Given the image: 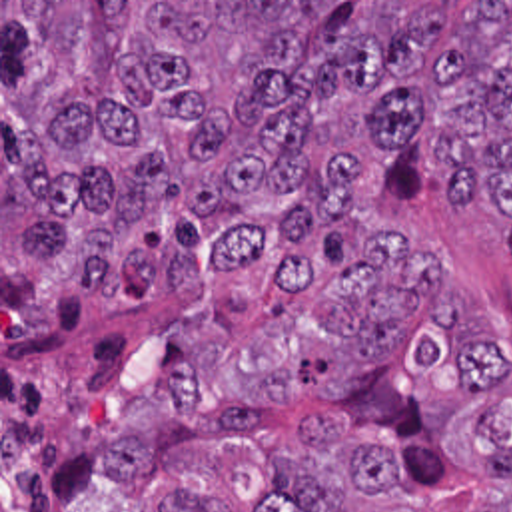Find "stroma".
Wrapping results in <instances>:
<instances>
[{
  "label": "stroma",
  "mask_w": 512,
  "mask_h": 512,
  "mask_svg": "<svg viewBox=\"0 0 512 512\" xmlns=\"http://www.w3.org/2000/svg\"><path fill=\"white\" fill-rule=\"evenodd\" d=\"M2 2H445L455 34L469 2L512 0H0V512H150L176 469L218 481L230 512H252L270 455L299 445L303 415H321L405 467V491L345 512H511L512 483L467 459L465 417L511 401L512 252L495 204L449 200L445 168L413 146L357 154L355 210L286 244H262L244 268L212 271L204 291L162 283L142 307L108 291L64 293L30 325H2ZM445 262V287L407 327L397 353L347 389H319L315 371L337 335L315 297L367 262L371 240L401 234ZM465 293L489 329L499 377L467 387L453 359L411 363L407 341L441 327ZM200 413L256 411L254 439H176L146 483H114L106 449L120 413L192 371Z\"/></svg>",
  "instance_id": "obj_1"
}]
</instances>
